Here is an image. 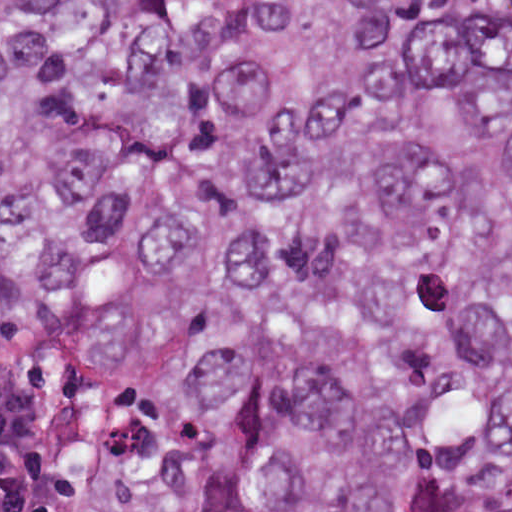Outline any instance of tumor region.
Here are the masks:
<instances>
[{"mask_svg": "<svg viewBox=\"0 0 512 512\" xmlns=\"http://www.w3.org/2000/svg\"><path fill=\"white\" fill-rule=\"evenodd\" d=\"M0 512H512V0H0Z\"/></svg>", "mask_w": 512, "mask_h": 512, "instance_id": "e687c5a6", "label": "tumor region"}]
</instances>
